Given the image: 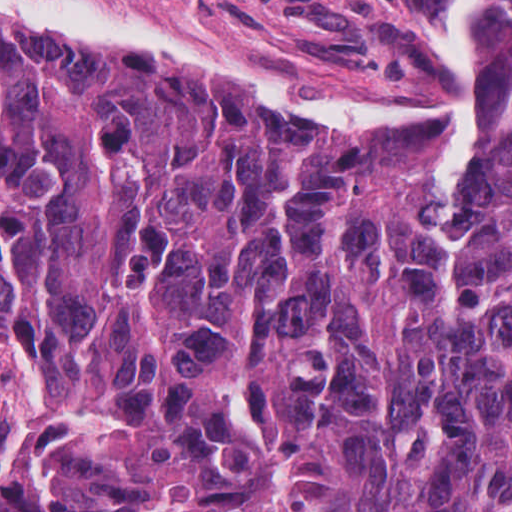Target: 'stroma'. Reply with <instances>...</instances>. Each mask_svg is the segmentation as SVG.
I'll use <instances>...</instances> for the list:
<instances>
[{"label":"stroma","instance_id":"35a3bbf8","mask_svg":"<svg viewBox=\"0 0 512 512\" xmlns=\"http://www.w3.org/2000/svg\"><path fill=\"white\" fill-rule=\"evenodd\" d=\"M118 1L155 11L212 40L277 59L365 96L407 101L452 97L461 91L462 81L444 57L460 0ZM477 1L480 94L481 42L493 0ZM424 132L435 142L438 179L436 139ZM477 177L478 131L457 179L441 185L456 198Z\"/></svg>","mask_w":512,"mask_h":512}]
</instances>
